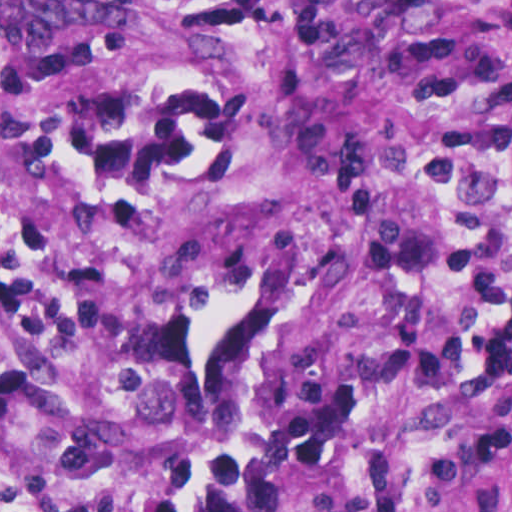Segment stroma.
I'll use <instances>...</instances> for the list:
<instances>
[{"instance_id":"1","label":"stroma","mask_w":512,"mask_h":512,"mask_svg":"<svg viewBox=\"0 0 512 512\" xmlns=\"http://www.w3.org/2000/svg\"><path fill=\"white\" fill-rule=\"evenodd\" d=\"M0 512H512V0H0Z\"/></svg>"}]
</instances>
